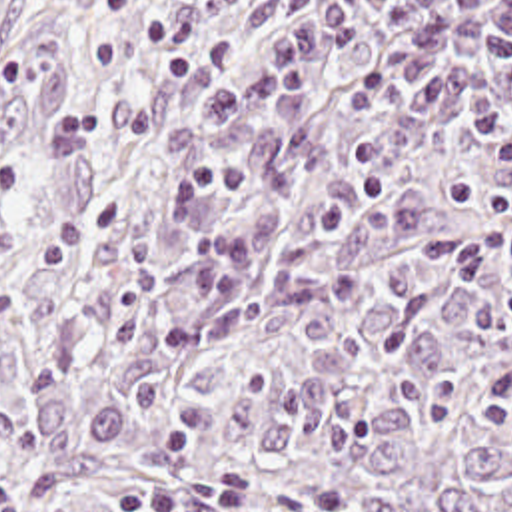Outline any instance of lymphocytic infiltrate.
<instances>
[{
	"instance_id": "lymphocytic-infiltrate-1",
	"label": "lymphocytic infiltrate",
	"mask_w": 512,
	"mask_h": 512,
	"mask_svg": "<svg viewBox=\"0 0 512 512\" xmlns=\"http://www.w3.org/2000/svg\"><path fill=\"white\" fill-rule=\"evenodd\" d=\"M372 11L400 23L404 45L352 85L348 107L360 123L384 121L396 103H410L414 113L448 111L464 95L472 65L491 57L512 63V0H334L276 31L254 67L228 91L188 105L170 131V185L156 221L174 261L258 267L298 255L384 207L388 189L374 183L326 205L306 225H260L232 245H216L200 231L206 193L254 191L270 181L260 165L208 163L200 143L224 123L258 115L318 61L352 47L358 19Z\"/></svg>"
}]
</instances>
